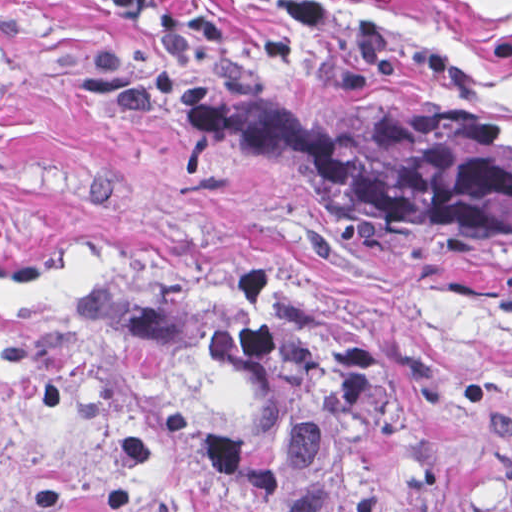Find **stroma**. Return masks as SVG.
Instances as JSON below:
<instances>
[{
    "instance_id": "35a3bbf8",
    "label": "stroma",
    "mask_w": 512,
    "mask_h": 512,
    "mask_svg": "<svg viewBox=\"0 0 512 512\" xmlns=\"http://www.w3.org/2000/svg\"><path fill=\"white\" fill-rule=\"evenodd\" d=\"M0 0V512H246L196 436L248 418L105 277L268 284L386 361L512 512V247L270 185L200 90L326 72L512 97V0Z\"/></svg>"
}]
</instances>
